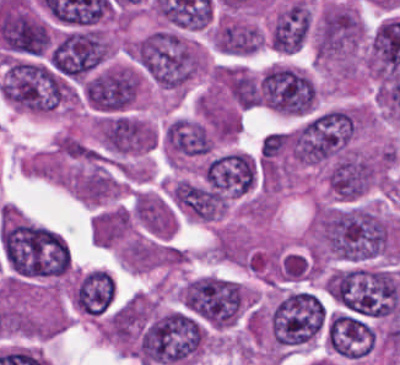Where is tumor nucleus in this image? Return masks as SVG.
Wrapping results in <instances>:
<instances>
[{
    "label": "tumor nucleus",
    "mask_w": 400,
    "mask_h": 365,
    "mask_svg": "<svg viewBox=\"0 0 400 365\" xmlns=\"http://www.w3.org/2000/svg\"><path fill=\"white\" fill-rule=\"evenodd\" d=\"M201 322L177 310L158 313L143 324L137 357L145 365H175L194 360L202 348Z\"/></svg>",
    "instance_id": "1"
},
{
    "label": "tumor nucleus",
    "mask_w": 400,
    "mask_h": 365,
    "mask_svg": "<svg viewBox=\"0 0 400 365\" xmlns=\"http://www.w3.org/2000/svg\"><path fill=\"white\" fill-rule=\"evenodd\" d=\"M354 128V112L338 107L321 110L287 133L288 153L303 165H321L349 145Z\"/></svg>",
    "instance_id": "2"
},
{
    "label": "tumor nucleus",
    "mask_w": 400,
    "mask_h": 365,
    "mask_svg": "<svg viewBox=\"0 0 400 365\" xmlns=\"http://www.w3.org/2000/svg\"><path fill=\"white\" fill-rule=\"evenodd\" d=\"M271 340L282 349L310 344L324 330L325 304L307 290L281 292L267 314Z\"/></svg>",
    "instance_id": "3"
},
{
    "label": "tumor nucleus",
    "mask_w": 400,
    "mask_h": 365,
    "mask_svg": "<svg viewBox=\"0 0 400 365\" xmlns=\"http://www.w3.org/2000/svg\"><path fill=\"white\" fill-rule=\"evenodd\" d=\"M247 290L243 283L217 274L191 278L179 291L181 306L211 327L223 328L239 320Z\"/></svg>",
    "instance_id": "4"
},
{
    "label": "tumor nucleus",
    "mask_w": 400,
    "mask_h": 365,
    "mask_svg": "<svg viewBox=\"0 0 400 365\" xmlns=\"http://www.w3.org/2000/svg\"><path fill=\"white\" fill-rule=\"evenodd\" d=\"M112 53L108 37L100 28L65 31L52 40L46 53L51 70L71 82H80Z\"/></svg>",
    "instance_id": "5"
},
{
    "label": "tumor nucleus",
    "mask_w": 400,
    "mask_h": 365,
    "mask_svg": "<svg viewBox=\"0 0 400 365\" xmlns=\"http://www.w3.org/2000/svg\"><path fill=\"white\" fill-rule=\"evenodd\" d=\"M364 37L357 10L342 3L325 6L315 23V54L324 63H349Z\"/></svg>",
    "instance_id": "6"
},
{
    "label": "tumor nucleus",
    "mask_w": 400,
    "mask_h": 365,
    "mask_svg": "<svg viewBox=\"0 0 400 365\" xmlns=\"http://www.w3.org/2000/svg\"><path fill=\"white\" fill-rule=\"evenodd\" d=\"M380 176L376 157L349 149L331 161L326 184L335 196L354 200L379 183Z\"/></svg>",
    "instance_id": "7"
},
{
    "label": "tumor nucleus",
    "mask_w": 400,
    "mask_h": 365,
    "mask_svg": "<svg viewBox=\"0 0 400 365\" xmlns=\"http://www.w3.org/2000/svg\"><path fill=\"white\" fill-rule=\"evenodd\" d=\"M94 131L101 147L121 155L150 149L155 137V130L147 121L122 112L99 116Z\"/></svg>",
    "instance_id": "8"
},
{
    "label": "tumor nucleus",
    "mask_w": 400,
    "mask_h": 365,
    "mask_svg": "<svg viewBox=\"0 0 400 365\" xmlns=\"http://www.w3.org/2000/svg\"><path fill=\"white\" fill-rule=\"evenodd\" d=\"M311 6L293 0L276 11L269 29L268 44L283 53H293L306 41L311 28Z\"/></svg>",
    "instance_id": "9"
},
{
    "label": "tumor nucleus",
    "mask_w": 400,
    "mask_h": 365,
    "mask_svg": "<svg viewBox=\"0 0 400 365\" xmlns=\"http://www.w3.org/2000/svg\"><path fill=\"white\" fill-rule=\"evenodd\" d=\"M115 295L110 272L95 268L79 274L72 286V302L87 316H100L111 305Z\"/></svg>",
    "instance_id": "10"
},
{
    "label": "tumor nucleus",
    "mask_w": 400,
    "mask_h": 365,
    "mask_svg": "<svg viewBox=\"0 0 400 365\" xmlns=\"http://www.w3.org/2000/svg\"><path fill=\"white\" fill-rule=\"evenodd\" d=\"M256 26L227 21L219 27V48L227 54L247 55L256 51L262 41Z\"/></svg>",
    "instance_id": "11"
}]
</instances>
